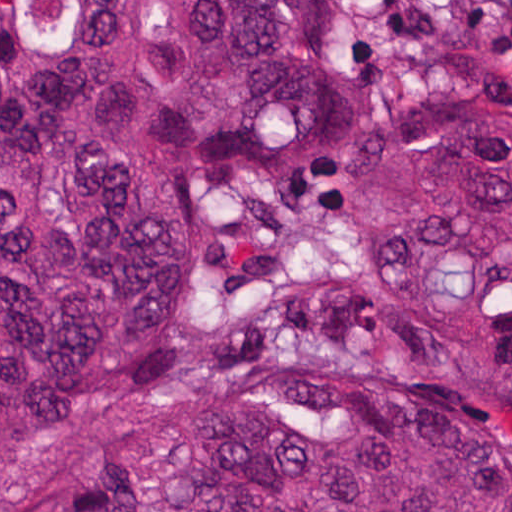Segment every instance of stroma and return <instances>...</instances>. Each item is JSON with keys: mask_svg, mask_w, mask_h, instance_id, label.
<instances>
[{"mask_svg": "<svg viewBox=\"0 0 512 512\" xmlns=\"http://www.w3.org/2000/svg\"><path fill=\"white\" fill-rule=\"evenodd\" d=\"M355 89L349 123L311 163L250 186L198 280V318L232 327L319 277L327 198L361 147L393 131L512 125V50L458 31L462 0H316Z\"/></svg>", "mask_w": 512, "mask_h": 512, "instance_id": "obj_1", "label": "stroma"}]
</instances>
